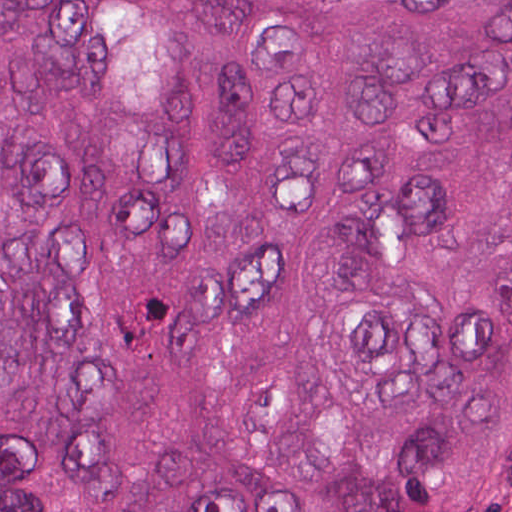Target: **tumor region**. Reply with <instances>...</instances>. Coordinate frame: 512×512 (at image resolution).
Wrapping results in <instances>:
<instances>
[{
  "label": "tumor region",
  "instance_id": "e687c5a6",
  "mask_svg": "<svg viewBox=\"0 0 512 512\" xmlns=\"http://www.w3.org/2000/svg\"><path fill=\"white\" fill-rule=\"evenodd\" d=\"M0 512H512V1H0Z\"/></svg>",
  "mask_w": 512,
  "mask_h": 512
}]
</instances>
